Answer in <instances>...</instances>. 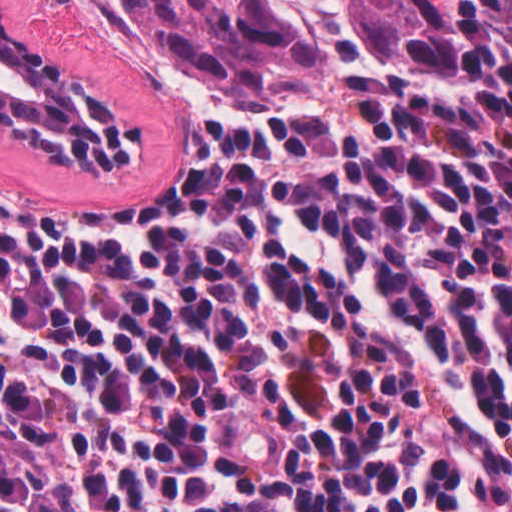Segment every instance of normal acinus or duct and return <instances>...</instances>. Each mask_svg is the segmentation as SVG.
<instances>
[{
  "mask_svg": "<svg viewBox=\"0 0 512 512\" xmlns=\"http://www.w3.org/2000/svg\"><path fill=\"white\" fill-rule=\"evenodd\" d=\"M0 130L53 167H114L139 148L138 117L58 62L1 5Z\"/></svg>",
  "mask_w": 512,
  "mask_h": 512,
  "instance_id": "obj_1",
  "label": "normal acinus or duct"
}]
</instances>
